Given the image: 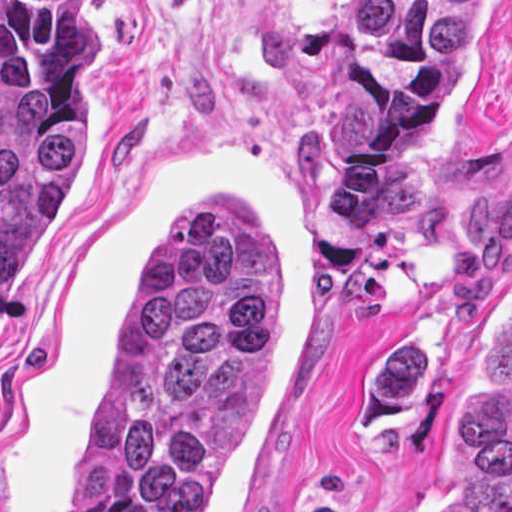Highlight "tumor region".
<instances>
[{
	"label": "tumor region",
	"mask_w": 512,
	"mask_h": 512,
	"mask_svg": "<svg viewBox=\"0 0 512 512\" xmlns=\"http://www.w3.org/2000/svg\"><path fill=\"white\" fill-rule=\"evenodd\" d=\"M504 0H334L331 226L381 252L420 200ZM94 0H0V314L83 163ZM278 400V279L250 204H202L90 384L76 512H207ZM432 512H512V283L444 391Z\"/></svg>",
	"instance_id": "1"
}]
</instances>
